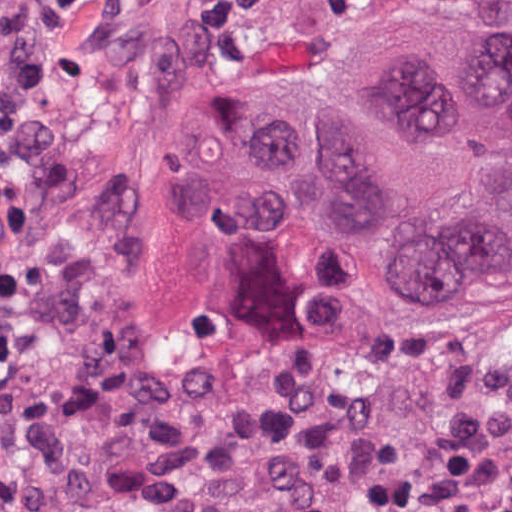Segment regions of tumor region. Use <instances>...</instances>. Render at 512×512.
<instances>
[{
	"label": "tumor region",
	"instance_id": "e687c5a6",
	"mask_svg": "<svg viewBox=\"0 0 512 512\" xmlns=\"http://www.w3.org/2000/svg\"><path fill=\"white\" fill-rule=\"evenodd\" d=\"M209 92L157 165L166 205L252 231L305 212L361 246L404 327L512 300V30L411 22L310 83Z\"/></svg>",
	"mask_w": 512,
	"mask_h": 512
}]
</instances>
